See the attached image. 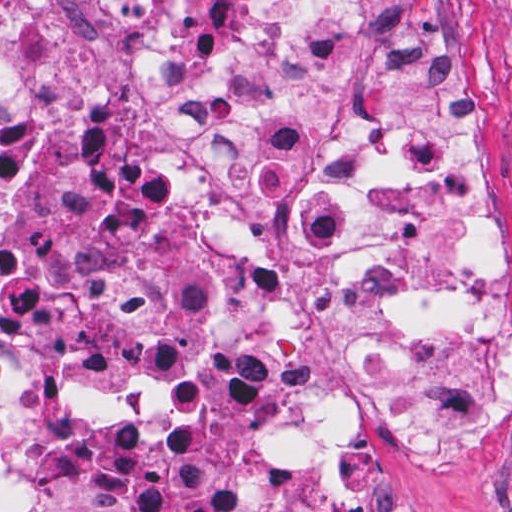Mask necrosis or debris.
I'll return each mask as SVG.
<instances>
[{"label":"necrosis or debris","instance_id":"4bbe7bcc","mask_svg":"<svg viewBox=\"0 0 512 512\" xmlns=\"http://www.w3.org/2000/svg\"><path fill=\"white\" fill-rule=\"evenodd\" d=\"M454 0H0V512H362L505 424Z\"/></svg>","mask_w":512,"mask_h":512}]
</instances>
